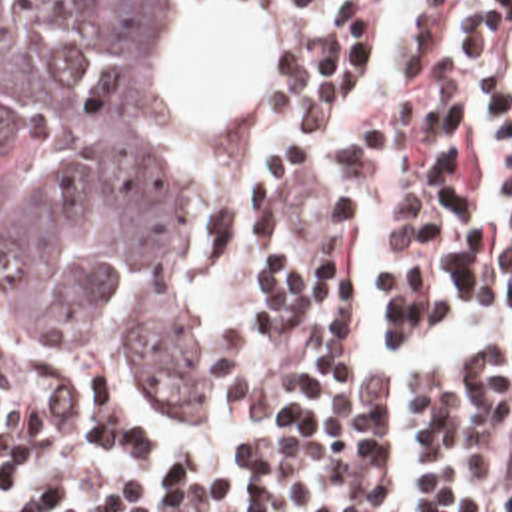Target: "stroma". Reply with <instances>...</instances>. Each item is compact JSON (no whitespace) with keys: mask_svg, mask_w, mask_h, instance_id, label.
<instances>
[{"mask_svg":"<svg viewBox=\"0 0 512 512\" xmlns=\"http://www.w3.org/2000/svg\"><path fill=\"white\" fill-rule=\"evenodd\" d=\"M203 0H175L167 79L173 95V181L197 221L193 291L199 305L211 261L227 237V195L247 107H227L219 71L205 49ZM0 355L17 357L45 387L81 409L127 427L135 421L105 365L69 341H41L19 333V297L0 255Z\"/></svg>","mask_w":512,"mask_h":512,"instance_id":"stroma-1","label":"stroma"}]
</instances>
